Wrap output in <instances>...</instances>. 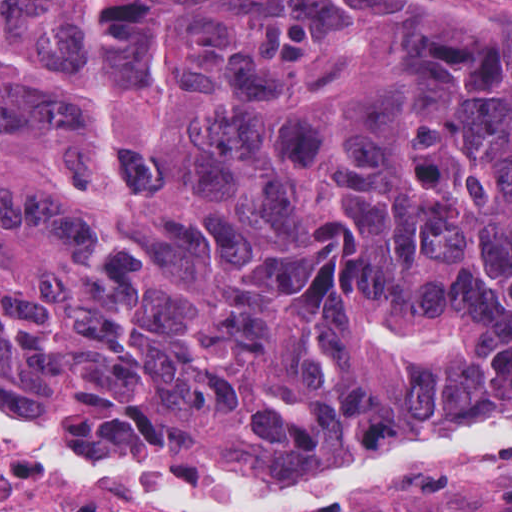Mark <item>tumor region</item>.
Listing matches in <instances>:
<instances>
[{
    "instance_id": "tumor-region-1",
    "label": "tumor region",
    "mask_w": 512,
    "mask_h": 512,
    "mask_svg": "<svg viewBox=\"0 0 512 512\" xmlns=\"http://www.w3.org/2000/svg\"><path fill=\"white\" fill-rule=\"evenodd\" d=\"M0 401L285 477L511 417L512 42L353 0H0ZM25 490L0 466V512Z\"/></svg>"
}]
</instances>
